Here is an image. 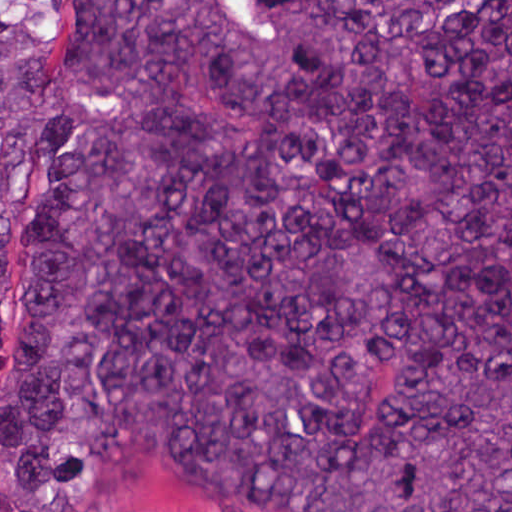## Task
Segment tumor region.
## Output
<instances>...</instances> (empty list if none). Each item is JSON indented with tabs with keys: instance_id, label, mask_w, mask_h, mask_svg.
<instances>
[{
	"instance_id": "tumor-region-1",
	"label": "tumor region",
	"mask_w": 512,
	"mask_h": 512,
	"mask_svg": "<svg viewBox=\"0 0 512 512\" xmlns=\"http://www.w3.org/2000/svg\"><path fill=\"white\" fill-rule=\"evenodd\" d=\"M0 362V512H512V1L0 15Z\"/></svg>"
}]
</instances>
